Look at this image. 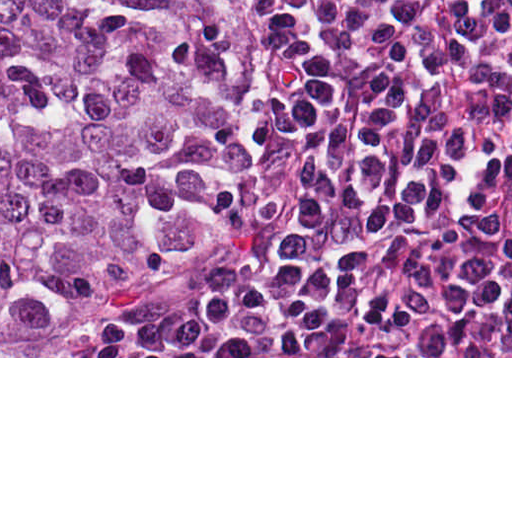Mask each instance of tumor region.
Returning <instances> with one entry per match:
<instances>
[{"label":"tumor region","instance_id":"1","mask_svg":"<svg viewBox=\"0 0 512 512\" xmlns=\"http://www.w3.org/2000/svg\"><path fill=\"white\" fill-rule=\"evenodd\" d=\"M277 59L237 0H0V356H115L286 249L305 161L253 105Z\"/></svg>","mask_w":512,"mask_h":512}]
</instances>
